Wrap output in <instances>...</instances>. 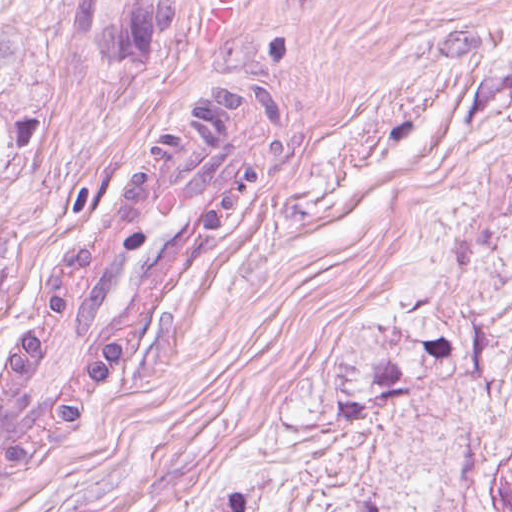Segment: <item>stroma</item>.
Here are the masks:
<instances>
[{
	"label": "stroma",
	"instance_id": "obj_1",
	"mask_svg": "<svg viewBox=\"0 0 512 512\" xmlns=\"http://www.w3.org/2000/svg\"><path fill=\"white\" fill-rule=\"evenodd\" d=\"M0 0V512H446L512 283V0ZM457 347L286 428L330 370Z\"/></svg>",
	"mask_w": 512,
	"mask_h": 512
}]
</instances>
